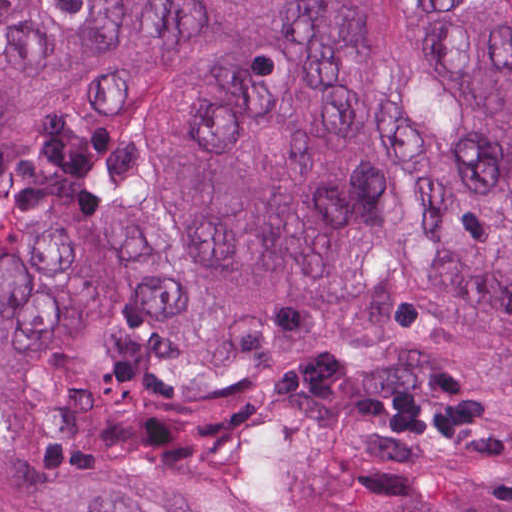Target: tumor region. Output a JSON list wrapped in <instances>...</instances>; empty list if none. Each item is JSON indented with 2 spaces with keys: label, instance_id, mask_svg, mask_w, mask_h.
I'll return each mask as SVG.
<instances>
[{
  "label": "tumor region",
  "instance_id": "obj_1",
  "mask_svg": "<svg viewBox=\"0 0 512 512\" xmlns=\"http://www.w3.org/2000/svg\"><path fill=\"white\" fill-rule=\"evenodd\" d=\"M0 512H512V0H0Z\"/></svg>",
  "mask_w": 512,
  "mask_h": 512
}]
</instances>
